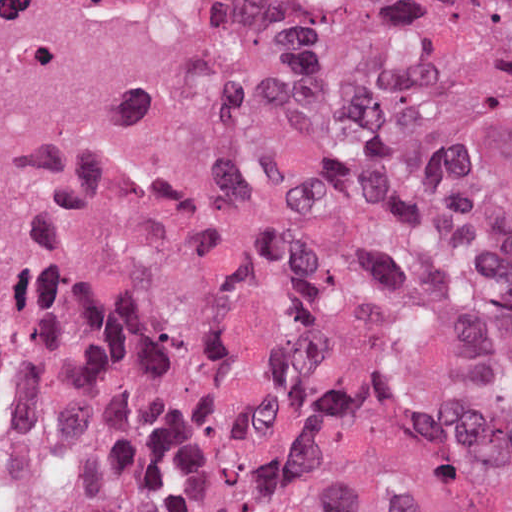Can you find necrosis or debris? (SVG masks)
Returning <instances> with one entry per match:
<instances>
[{
  "label": "necrosis or debris",
  "mask_w": 512,
  "mask_h": 512,
  "mask_svg": "<svg viewBox=\"0 0 512 512\" xmlns=\"http://www.w3.org/2000/svg\"><path fill=\"white\" fill-rule=\"evenodd\" d=\"M283 107L239 0H0V339Z\"/></svg>",
  "instance_id": "1"
}]
</instances>
